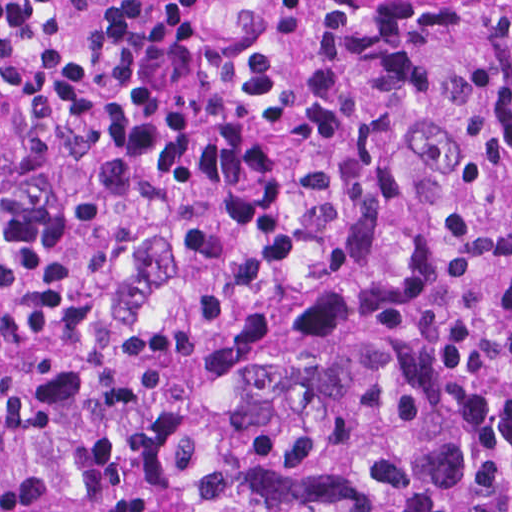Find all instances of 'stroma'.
<instances>
[{"label": "stroma", "mask_w": 512, "mask_h": 512, "mask_svg": "<svg viewBox=\"0 0 512 512\" xmlns=\"http://www.w3.org/2000/svg\"><path fill=\"white\" fill-rule=\"evenodd\" d=\"M334 0H218L211 13V28L228 46L258 55H297L308 51L312 37ZM460 1L451 0V12L434 32L422 41L407 60L401 73V104L386 142V199L395 170V140L401 111L409 88L418 77L428 55L440 47L451 14ZM509 3L512 0H482ZM378 249L377 240L369 245L352 248L343 253L319 257L289 259L277 266L252 270L229 271L193 250L167 248L149 270L135 281L127 293L113 304L126 298L157 272L172 269L187 262H207L230 277L242 275H276L312 265L353 258ZM112 304V305H113ZM111 305V306H112Z\"/></svg>", "instance_id": "obj_1"}]
</instances>
